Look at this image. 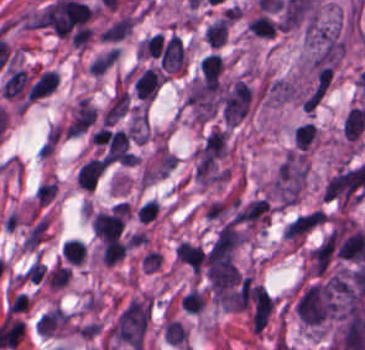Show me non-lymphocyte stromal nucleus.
<instances>
[{
  "label": "non-lymphocyte stromal nucleus",
  "instance_id": "non-lymphocyte-stromal-nucleus-1",
  "mask_svg": "<svg viewBox=\"0 0 365 350\" xmlns=\"http://www.w3.org/2000/svg\"><path fill=\"white\" fill-rule=\"evenodd\" d=\"M274 310V301L262 288L256 285L252 292V326L262 331Z\"/></svg>",
  "mask_w": 365,
  "mask_h": 350
},
{
  "label": "non-lymphocyte stromal nucleus",
  "instance_id": "non-lymphocyte-stromal-nucleus-2",
  "mask_svg": "<svg viewBox=\"0 0 365 350\" xmlns=\"http://www.w3.org/2000/svg\"><path fill=\"white\" fill-rule=\"evenodd\" d=\"M318 212H310L297 216L286 226L284 233L287 238H295L305 234L317 221Z\"/></svg>",
  "mask_w": 365,
  "mask_h": 350
},
{
  "label": "non-lymphocyte stromal nucleus",
  "instance_id": "non-lymphocyte-stromal-nucleus-3",
  "mask_svg": "<svg viewBox=\"0 0 365 350\" xmlns=\"http://www.w3.org/2000/svg\"><path fill=\"white\" fill-rule=\"evenodd\" d=\"M27 82V76L22 69H18L15 72L9 74L5 82L0 88V93L7 98L19 97Z\"/></svg>",
  "mask_w": 365,
  "mask_h": 350
}]
</instances>
